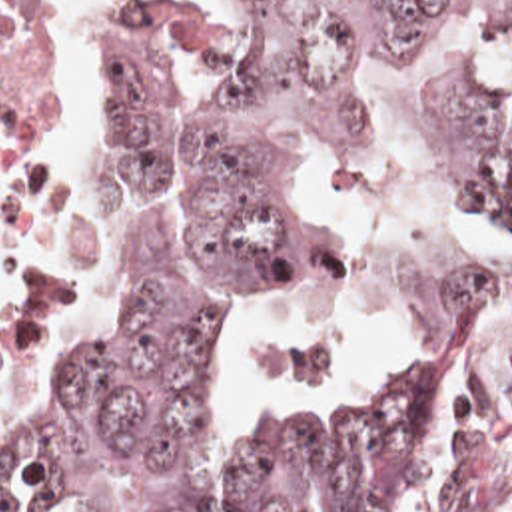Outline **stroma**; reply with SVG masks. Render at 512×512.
<instances>
[{"mask_svg":"<svg viewBox=\"0 0 512 512\" xmlns=\"http://www.w3.org/2000/svg\"><path fill=\"white\" fill-rule=\"evenodd\" d=\"M109 2L101 0L95 18L85 20L75 10L77 0H49V206L35 240L23 308L0 354V372L23 328L65 170L83 140L99 144V40Z\"/></svg>","mask_w":512,"mask_h":512,"instance_id":"obj_1","label":"stroma"}]
</instances>
